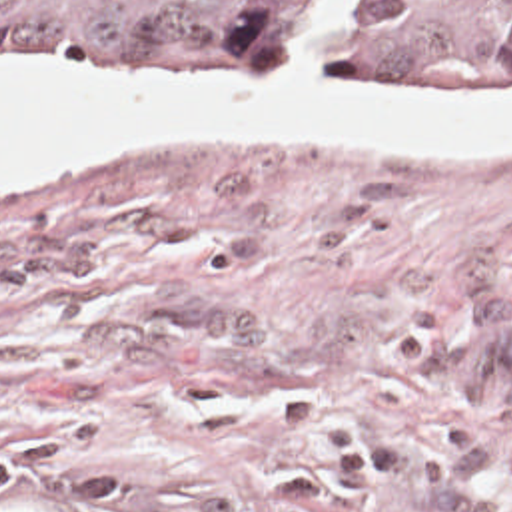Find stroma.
<instances>
[{
	"label": "stroma",
	"instance_id": "1",
	"mask_svg": "<svg viewBox=\"0 0 512 512\" xmlns=\"http://www.w3.org/2000/svg\"><path fill=\"white\" fill-rule=\"evenodd\" d=\"M407 91L419 77H208ZM0 490L30 512H512V143L198 133L0 195Z\"/></svg>",
	"mask_w": 512,
	"mask_h": 512
}]
</instances>
